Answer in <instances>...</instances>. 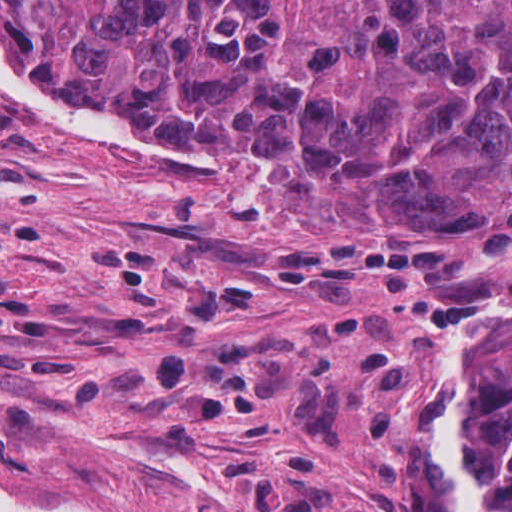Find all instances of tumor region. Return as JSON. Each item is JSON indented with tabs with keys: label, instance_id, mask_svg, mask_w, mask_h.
Instances as JSON below:
<instances>
[{
	"label": "tumor region",
	"instance_id": "tumor-region-1",
	"mask_svg": "<svg viewBox=\"0 0 512 512\" xmlns=\"http://www.w3.org/2000/svg\"><path fill=\"white\" fill-rule=\"evenodd\" d=\"M0 55L206 137L362 241L512 237V0H0ZM493 512H512V342Z\"/></svg>",
	"mask_w": 512,
	"mask_h": 512
}]
</instances>
